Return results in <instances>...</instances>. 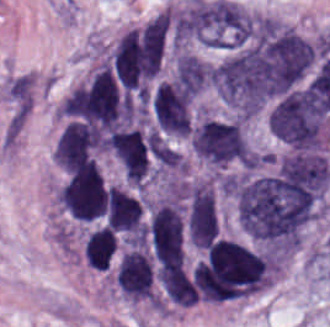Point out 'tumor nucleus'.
I'll list each match as a JSON object with an SVG mask.
<instances>
[{"label": "tumor nucleus", "instance_id": "obj_1", "mask_svg": "<svg viewBox=\"0 0 330 327\" xmlns=\"http://www.w3.org/2000/svg\"><path fill=\"white\" fill-rule=\"evenodd\" d=\"M190 144L205 163L250 166L252 153L244 123L238 117L200 113L190 124Z\"/></svg>", "mask_w": 330, "mask_h": 327}, {"label": "tumor nucleus", "instance_id": "obj_2", "mask_svg": "<svg viewBox=\"0 0 330 327\" xmlns=\"http://www.w3.org/2000/svg\"><path fill=\"white\" fill-rule=\"evenodd\" d=\"M99 141L96 131L79 118L65 122L55 139L58 163L69 168L93 163Z\"/></svg>", "mask_w": 330, "mask_h": 327}, {"label": "tumor nucleus", "instance_id": "obj_3", "mask_svg": "<svg viewBox=\"0 0 330 327\" xmlns=\"http://www.w3.org/2000/svg\"><path fill=\"white\" fill-rule=\"evenodd\" d=\"M117 245L116 231L108 226L89 228L82 241L85 261L95 270H104L110 263Z\"/></svg>", "mask_w": 330, "mask_h": 327}, {"label": "tumor nucleus", "instance_id": "obj_4", "mask_svg": "<svg viewBox=\"0 0 330 327\" xmlns=\"http://www.w3.org/2000/svg\"><path fill=\"white\" fill-rule=\"evenodd\" d=\"M209 68L193 53L179 52L174 69L176 84L192 94H196L207 83Z\"/></svg>", "mask_w": 330, "mask_h": 327}]
</instances>
